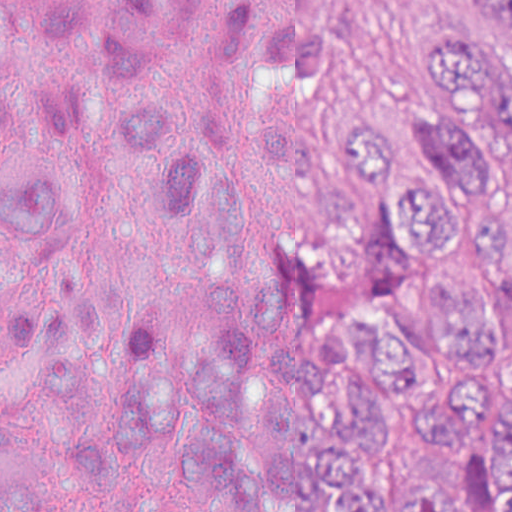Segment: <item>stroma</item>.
<instances>
[{"label": "stroma", "instance_id": "stroma-1", "mask_svg": "<svg viewBox=\"0 0 512 512\" xmlns=\"http://www.w3.org/2000/svg\"><path fill=\"white\" fill-rule=\"evenodd\" d=\"M104 1L119 10L132 33H153L137 23L160 33H193L240 4L313 19L328 43L323 70L277 104L292 123L336 152V185L313 200L288 190L264 199L263 230L239 268L277 273L293 287L287 328L266 343L272 400L292 402L291 346L320 312L304 275V229L344 212V129L355 115L419 119L430 104L434 40H474L489 23L477 0ZM0 166L63 199V229L42 250L16 255L0 241V403L12 383L2 306L18 277L34 270L95 273L112 301V327L84 394L72 411L36 421L38 459L54 455L74 424L91 420L108 430L104 408L128 307L148 311L184 335L203 324V283L213 275L182 270L168 253L161 223L143 203L132 173L96 135L77 84L47 44H0ZM119 447L126 483L105 494L70 487L57 500L64 512H126L146 500L216 512L210 497L171 489Z\"/></svg>", "mask_w": 512, "mask_h": 512}]
</instances>
